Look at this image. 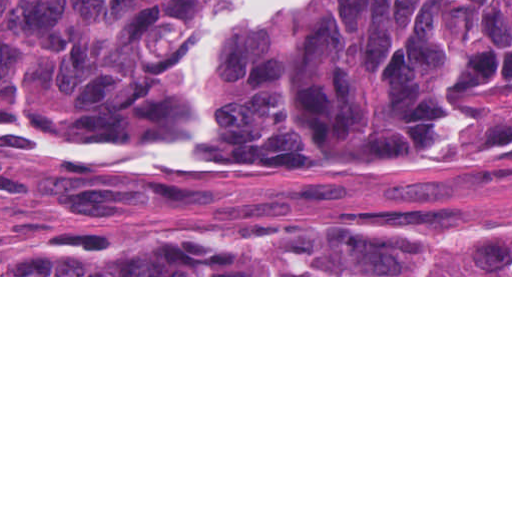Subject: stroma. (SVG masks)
Returning <instances> with one entry per match:
<instances>
[{"mask_svg": "<svg viewBox=\"0 0 512 512\" xmlns=\"http://www.w3.org/2000/svg\"><path fill=\"white\" fill-rule=\"evenodd\" d=\"M162 170V169H127ZM423 234L512 226V167L411 184L315 167L238 145L178 188L134 190L87 155L0 131V264L51 255L90 236H159L242 220ZM0 277H512V275H0Z\"/></svg>", "mask_w": 512, "mask_h": 512, "instance_id": "1", "label": "stroma"}]
</instances>
